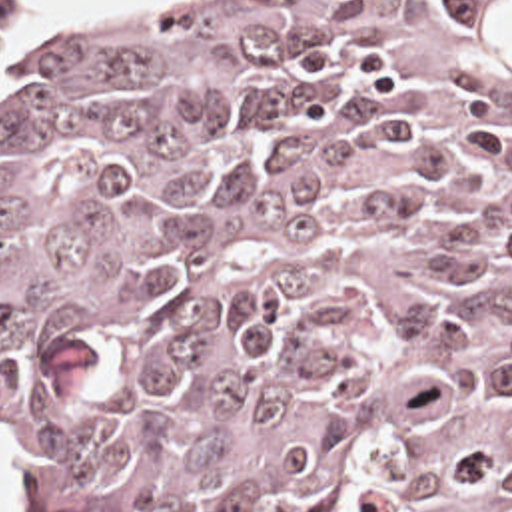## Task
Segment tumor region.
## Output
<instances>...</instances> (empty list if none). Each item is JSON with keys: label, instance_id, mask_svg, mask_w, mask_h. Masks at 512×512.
I'll return each instance as SVG.
<instances>
[{"label": "tumor region", "instance_id": "e687c5a6", "mask_svg": "<svg viewBox=\"0 0 512 512\" xmlns=\"http://www.w3.org/2000/svg\"><path fill=\"white\" fill-rule=\"evenodd\" d=\"M0 448L47 512H512V0L0 28Z\"/></svg>", "mask_w": 512, "mask_h": 512}]
</instances>
